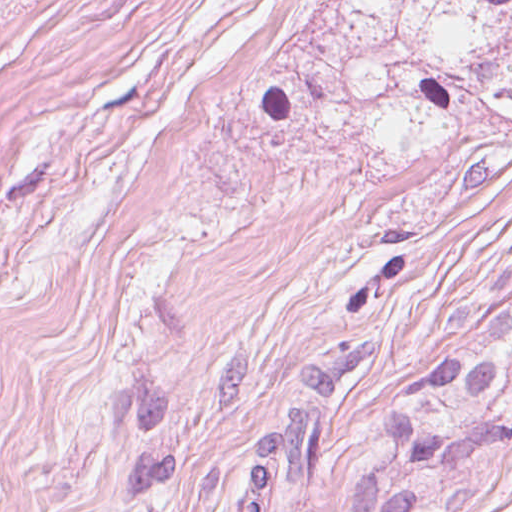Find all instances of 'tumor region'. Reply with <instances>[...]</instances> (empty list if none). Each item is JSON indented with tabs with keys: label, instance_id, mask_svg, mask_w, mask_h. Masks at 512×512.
<instances>
[{
	"label": "tumor region",
	"instance_id": "obj_1",
	"mask_svg": "<svg viewBox=\"0 0 512 512\" xmlns=\"http://www.w3.org/2000/svg\"><path fill=\"white\" fill-rule=\"evenodd\" d=\"M370 338L300 361L231 512H451L512 481V273L479 284L411 377L333 419Z\"/></svg>",
	"mask_w": 512,
	"mask_h": 512
}]
</instances>
